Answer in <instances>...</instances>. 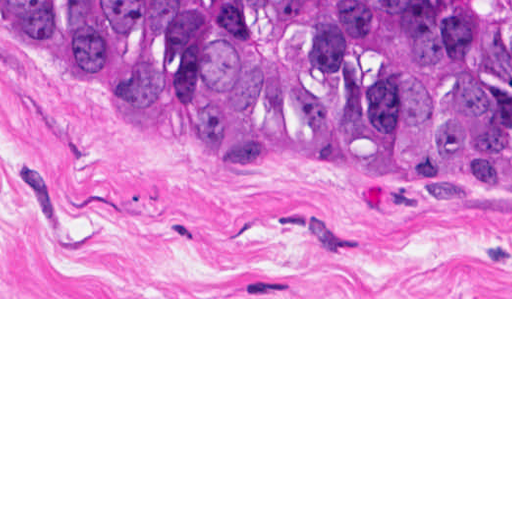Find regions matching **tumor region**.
I'll use <instances>...</instances> for the list:
<instances>
[{
	"label": "tumor region",
	"instance_id": "1",
	"mask_svg": "<svg viewBox=\"0 0 512 512\" xmlns=\"http://www.w3.org/2000/svg\"><path fill=\"white\" fill-rule=\"evenodd\" d=\"M0 35L300 160L512 161V0H0Z\"/></svg>",
	"mask_w": 512,
	"mask_h": 512
}]
</instances>
